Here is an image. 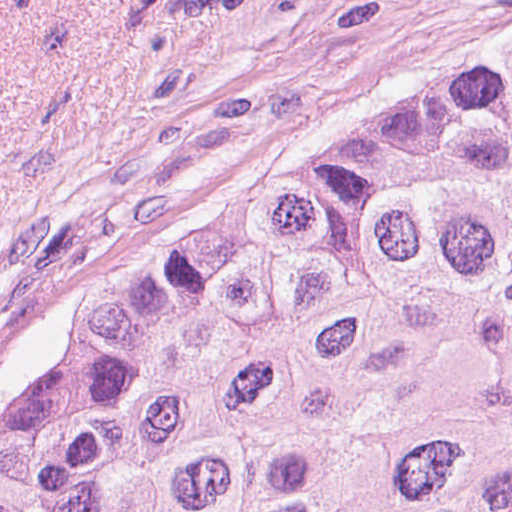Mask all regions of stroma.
Here are the masks:
<instances>
[{"label": "stroma", "mask_w": 512, "mask_h": 512, "mask_svg": "<svg viewBox=\"0 0 512 512\" xmlns=\"http://www.w3.org/2000/svg\"><path fill=\"white\" fill-rule=\"evenodd\" d=\"M512 51V0H0L1 407L207 214Z\"/></svg>", "instance_id": "stroma-1"}]
</instances>
